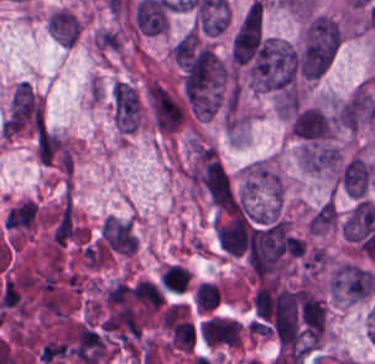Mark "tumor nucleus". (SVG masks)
I'll list each match as a JSON object with an SVG mask.
<instances>
[{
	"instance_id": "tumor-nucleus-2",
	"label": "tumor nucleus",
	"mask_w": 375,
	"mask_h": 364,
	"mask_svg": "<svg viewBox=\"0 0 375 364\" xmlns=\"http://www.w3.org/2000/svg\"><path fill=\"white\" fill-rule=\"evenodd\" d=\"M113 120L119 132H133L140 122V103L133 87L124 82L113 85L111 92Z\"/></svg>"
},
{
	"instance_id": "tumor-nucleus-1",
	"label": "tumor nucleus",
	"mask_w": 375,
	"mask_h": 364,
	"mask_svg": "<svg viewBox=\"0 0 375 364\" xmlns=\"http://www.w3.org/2000/svg\"><path fill=\"white\" fill-rule=\"evenodd\" d=\"M297 76L296 48L278 38H264L257 61L258 89L296 94Z\"/></svg>"
},
{
	"instance_id": "tumor-nucleus-3",
	"label": "tumor nucleus",
	"mask_w": 375,
	"mask_h": 364,
	"mask_svg": "<svg viewBox=\"0 0 375 364\" xmlns=\"http://www.w3.org/2000/svg\"><path fill=\"white\" fill-rule=\"evenodd\" d=\"M337 219V208L334 201H327L319 206L309 219L311 233H322L330 228Z\"/></svg>"
}]
</instances>
